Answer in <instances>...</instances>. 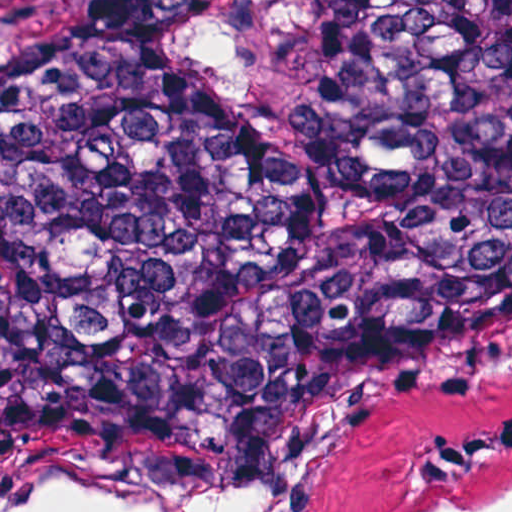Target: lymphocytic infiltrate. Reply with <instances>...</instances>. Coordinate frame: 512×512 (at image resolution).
I'll return each instance as SVG.
<instances>
[{"label":"lymphocytic infiltrate","instance_id":"f902f5d3","mask_svg":"<svg viewBox=\"0 0 512 512\" xmlns=\"http://www.w3.org/2000/svg\"><path fill=\"white\" fill-rule=\"evenodd\" d=\"M512 454V410L456 419L411 475L445 479L497 455Z\"/></svg>","mask_w":512,"mask_h":512}]
</instances>
